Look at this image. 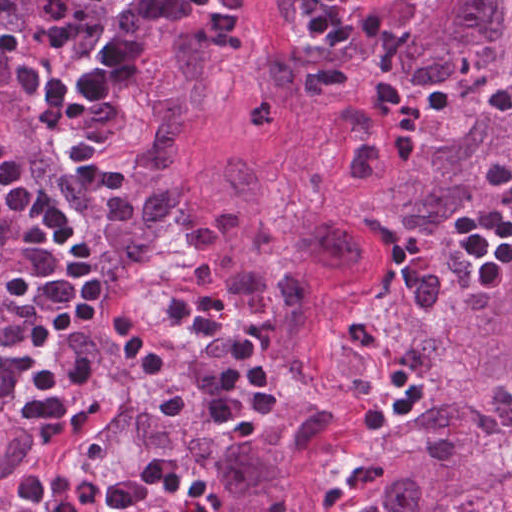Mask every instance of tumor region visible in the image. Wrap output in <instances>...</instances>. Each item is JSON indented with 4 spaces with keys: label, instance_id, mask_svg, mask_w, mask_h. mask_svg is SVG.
Returning a JSON list of instances; mask_svg holds the SVG:
<instances>
[{
    "label": "tumor region",
    "instance_id": "tumor-region-1",
    "mask_svg": "<svg viewBox=\"0 0 512 512\" xmlns=\"http://www.w3.org/2000/svg\"><path fill=\"white\" fill-rule=\"evenodd\" d=\"M149 131L130 173L71 169L59 191L122 287L184 244L194 276L163 315L181 341L159 373L312 512L342 454L376 470L371 512H512V260L498 297L473 282L459 217L512 199V0H423L388 52L334 97L309 189L262 220L257 171L240 159L201 202L183 170L186 133L214 114L220 77L182 31L134 80ZM283 273L218 284V258L273 264L299 210ZM222 297L282 379V403L257 437L220 422L224 349L176 320L194 282ZM422 406L365 431L360 416L392 392L390 365Z\"/></svg>",
    "mask_w": 512,
    "mask_h": 512
}]
</instances>
